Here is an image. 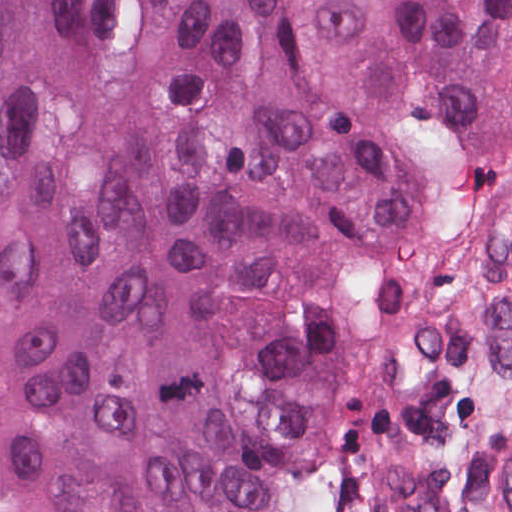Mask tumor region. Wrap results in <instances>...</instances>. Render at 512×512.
Masks as SVG:
<instances>
[{"instance_id": "1", "label": "tumor region", "mask_w": 512, "mask_h": 512, "mask_svg": "<svg viewBox=\"0 0 512 512\" xmlns=\"http://www.w3.org/2000/svg\"><path fill=\"white\" fill-rule=\"evenodd\" d=\"M512 154V0H0V512H303L311 396Z\"/></svg>"}]
</instances>
